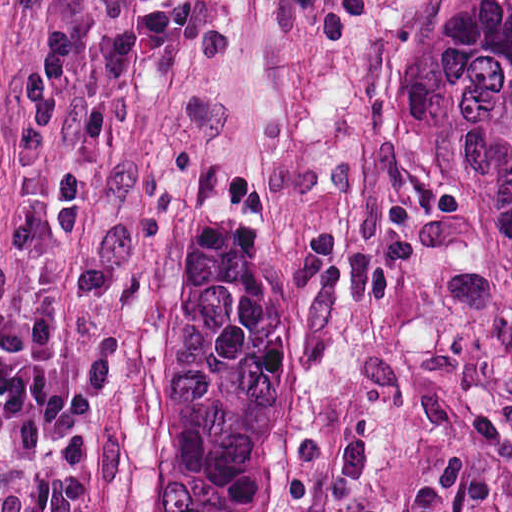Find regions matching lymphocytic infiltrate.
Returning <instances> with one entry per match:
<instances>
[{
  "label": "lymphocytic infiltrate",
  "mask_w": 512,
  "mask_h": 512,
  "mask_svg": "<svg viewBox=\"0 0 512 512\" xmlns=\"http://www.w3.org/2000/svg\"><path fill=\"white\" fill-rule=\"evenodd\" d=\"M369 0H286L315 49L329 52L369 18ZM137 26L101 43L87 76L107 100L121 96L144 59L177 52L198 29L200 0H144ZM78 80L69 33L55 24L21 82L24 106L11 148L22 176L44 188L57 241L81 242L83 180L62 155L67 105ZM370 453L337 432L309 456L295 512H355ZM93 363H55L26 335L20 299L0 265V512H92Z\"/></svg>",
  "instance_id": "obj_1"
}]
</instances>
